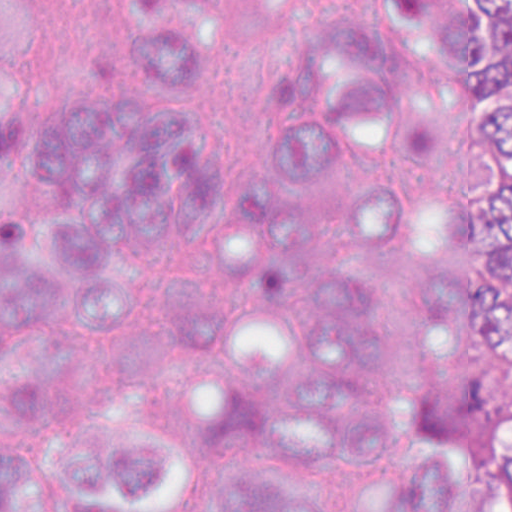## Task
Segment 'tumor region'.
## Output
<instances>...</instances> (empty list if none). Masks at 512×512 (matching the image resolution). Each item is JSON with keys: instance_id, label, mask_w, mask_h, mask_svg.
I'll return each instance as SVG.
<instances>
[{"instance_id": "obj_1", "label": "tumor region", "mask_w": 512, "mask_h": 512, "mask_svg": "<svg viewBox=\"0 0 512 512\" xmlns=\"http://www.w3.org/2000/svg\"><path fill=\"white\" fill-rule=\"evenodd\" d=\"M455 122L445 213L451 260L428 310L463 355L512 364V0H402ZM371 512H512V443L501 462L463 450L426 458Z\"/></svg>"}]
</instances>
